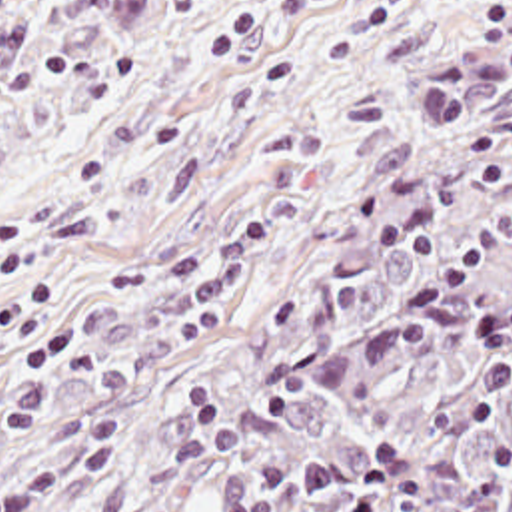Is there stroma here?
<instances>
[{"mask_svg": "<svg viewBox=\"0 0 512 512\" xmlns=\"http://www.w3.org/2000/svg\"><path fill=\"white\" fill-rule=\"evenodd\" d=\"M512 0H0V512L121 460L301 185Z\"/></svg>", "mask_w": 512, "mask_h": 512, "instance_id": "1", "label": "stroma"}]
</instances>
